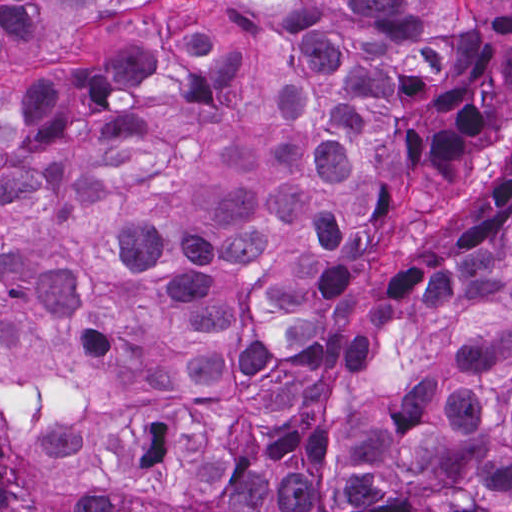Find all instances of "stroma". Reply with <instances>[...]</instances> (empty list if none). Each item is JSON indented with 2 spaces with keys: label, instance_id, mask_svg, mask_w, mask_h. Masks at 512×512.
Wrapping results in <instances>:
<instances>
[{
  "label": "stroma",
  "instance_id": "obj_1",
  "mask_svg": "<svg viewBox=\"0 0 512 512\" xmlns=\"http://www.w3.org/2000/svg\"><path fill=\"white\" fill-rule=\"evenodd\" d=\"M0 1H103L76 3L73 12L87 9L62 25L59 34L36 41L13 40L0 62V93L18 87L41 63L75 60L108 49L118 38L125 19L148 1H512V0H0Z\"/></svg>",
  "mask_w": 512,
  "mask_h": 512
}]
</instances>
